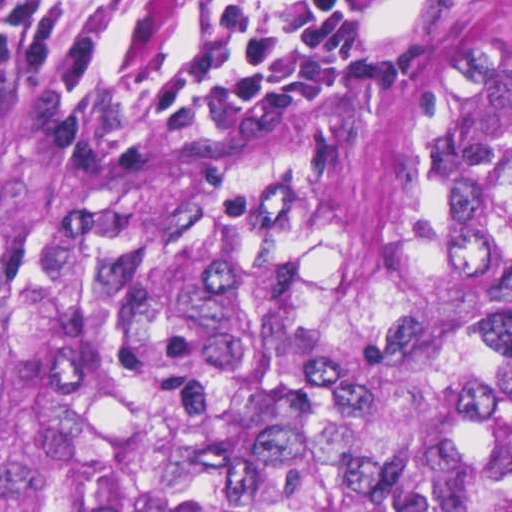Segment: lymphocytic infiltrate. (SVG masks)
<instances>
[{"mask_svg":"<svg viewBox=\"0 0 512 512\" xmlns=\"http://www.w3.org/2000/svg\"><path fill=\"white\" fill-rule=\"evenodd\" d=\"M371 0H0V68L118 95L275 102L337 61Z\"/></svg>","mask_w":512,"mask_h":512,"instance_id":"obj_1","label":"lymphocytic infiltrate"}]
</instances>
